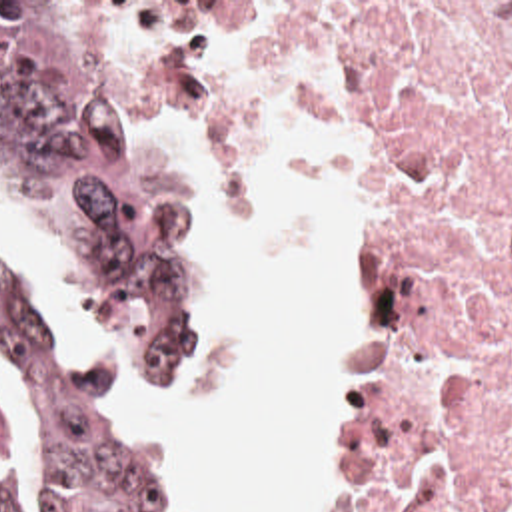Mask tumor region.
Returning <instances> with one entry per match:
<instances>
[{"label": "tumor region", "mask_w": 512, "mask_h": 512, "mask_svg": "<svg viewBox=\"0 0 512 512\" xmlns=\"http://www.w3.org/2000/svg\"><path fill=\"white\" fill-rule=\"evenodd\" d=\"M0 178L66 254L120 399L176 393L202 357V216L188 174L118 102L96 2H0ZM0 363L36 427L48 512H178L140 427L2 256ZM16 511L0 481V512Z\"/></svg>", "instance_id": "e687c5a6"}]
</instances>
